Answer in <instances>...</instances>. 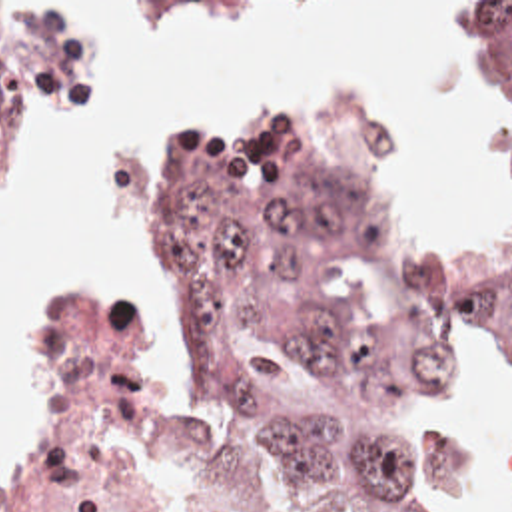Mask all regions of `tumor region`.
Segmentation results:
<instances>
[{
    "label": "tumor region",
    "instance_id": "tumor-region-1",
    "mask_svg": "<svg viewBox=\"0 0 512 512\" xmlns=\"http://www.w3.org/2000/svg\"><path fill=\"white\" fill-rule=\"evenodd\" d=\"M512 140V2H464ZM123 118V18L0 2V248L19 188ZM145 313L277 493L331 512H440L422 409L462 323L512 319V226L468 252L402 242L356 190V114L251 100L173 150Z\"/></svg>",
    "mask_w": 512,
    "mask_h": 512
}]
</instances>
